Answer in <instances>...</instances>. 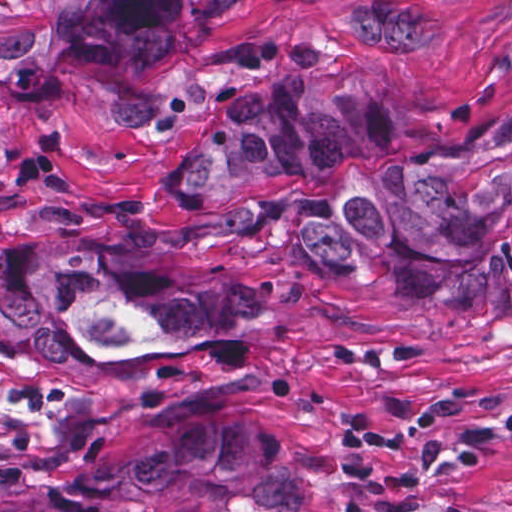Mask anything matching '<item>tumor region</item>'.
<instances>
[{
    "instance_id": "e687c5a6",
    "label": "tumor region",
    "mask_w": 512,
    "mask_h": 512,
    "mask_svg": "<svg viewBox=\"0 0 512 512\" xmlns=\"http://www.w3.org/2000/svg\"><path fill=\"white\" fill-rule=\"evenodd\" d=\"M234 0H1V77L88 57H174ZM317 63L241 91L178 176L246 200L307 178L329 196L312 249L444 305L512 320V107L447 140L414 137L367 76ZM1 319L90 363H178L185 348L271 339L281 309L217 265L82 227L1 241ZM302 474L248 427L163 434L1 512H300Z\"/></svg>"
}]
</instances>
